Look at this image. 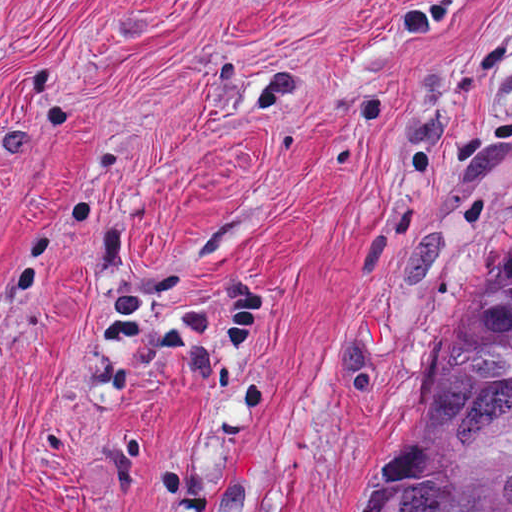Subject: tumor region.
<instances>
[{
    "label": "tumor region",
    "instance_id": "obj_1",
    "mask_svg": "<svg viewBox=\"0 0 512 512\" xmlns=\"http://www.w3.org/2000/svg\"><path fill=\"white\" fill-rule=\"evenodd\" d=\"M364 512H512V282Z\"/></svg>",
    "mask_w": 512,
    "mask_h": 512
}]
</instances>
